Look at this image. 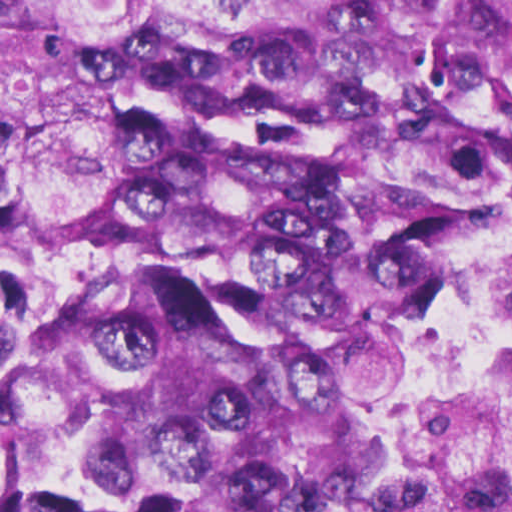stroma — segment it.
Masks as SVG:
<instances>
[{
  "mask_svg": "<svg viewBox=\"0 0 512 512\" xmlns=\"http://www.w3.org/2000/svg\"><path fill=\"white\" fill-rule=\"evenodd\" d=\"M511 199L499 253L458 298L424 322L392 364V490L382 512H427L434 367L446 364L489 326L512 231V157L490 172Z\"/></svg>",
  "mask_w": 512,
  "mask_h": 512,
  "instance_id": "35a3bbf8",
  "label": "stroma"
}]
</instances>
